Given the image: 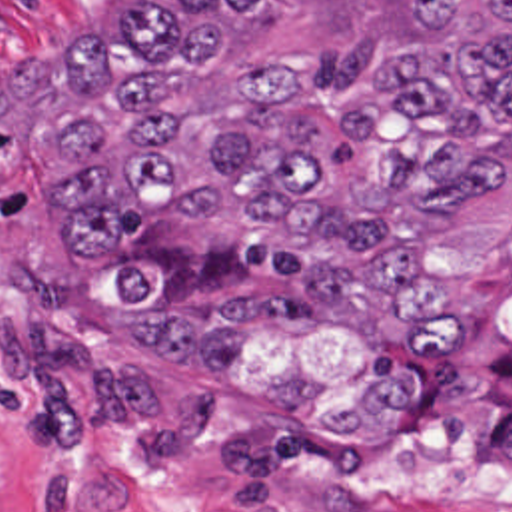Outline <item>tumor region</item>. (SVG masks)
Segmentation results:
<instances>
[{"instance_id":"e687c5a6","label":"tumor region","mask_w":512,"mask_h":512,"mask_svg":"<svg viewBox=\"0 0 512 512\" xmlns=\"http://www.w3.org/2000/svg\"><path fill=\"white\" fill-rule=\"evenodd\" d=\"M265 0H129L61 44L45 182L75 254L137 206L161 218L107 266V348L129 403L179 447H389L421 397V340L459 298L437 236L512 180V0H413L347 94L307 52H263L191 118L171 78L211 70ZM15 102L0 84V114Z\"/></svg>"}]
</instances>
